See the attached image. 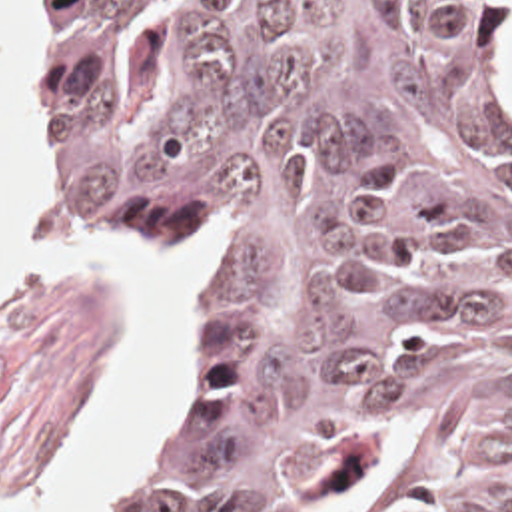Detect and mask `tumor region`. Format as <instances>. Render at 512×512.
I'll list each match as a JSON object with an SVG mask.
<instances>
[{
    "instance_id": "obj_1",
    "label": "tumor region",
    "mask_w": 512,
    "mask_h": 512,
    "mask_svg": "<svg viewBox=\"0 0 512 512\" xmlns=\"http://www.w3.org/2000/svg\"><path fill=\"white\" fill-rule=\"evenodd\" d=\"M500 5L53 0L55 187L221 257L151 512H512Z\"/></svg>"
}]
</instances>
